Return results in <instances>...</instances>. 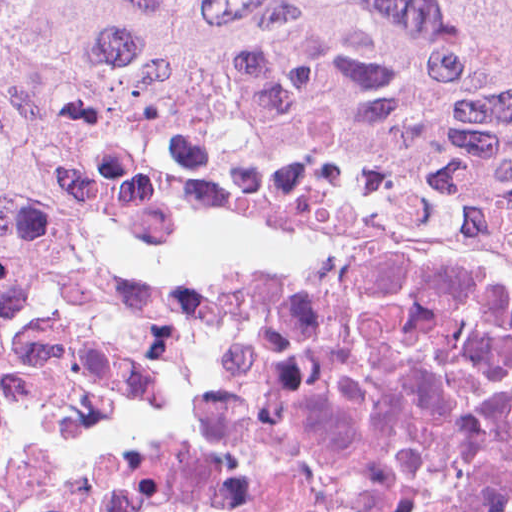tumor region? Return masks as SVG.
Here are the masks:
<instances>
[{
	"mask_svg": "<svg viewBox=\"0 0 512 512\" xmlns=\"http://www.w3.org/2000/svg\"><path fill=\"white\" fill-rule=\"evenodd\" d=\"M163 161L512 242V0H0V289Z\"/></svg>",
	"mask_w": 512,
	"mask_h": 512,
	"instance_id": "obj_1",
	"label": "tumor region"
}]
</instances>
